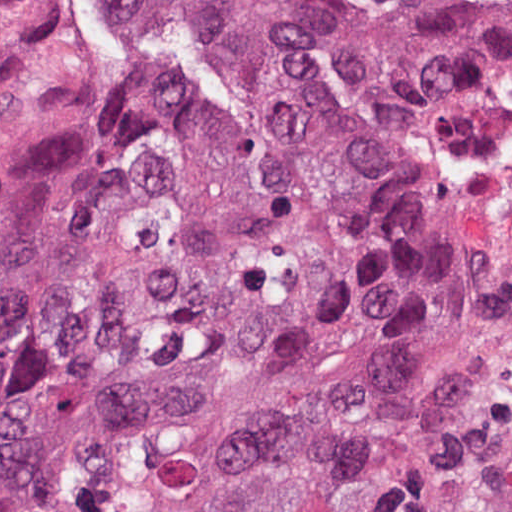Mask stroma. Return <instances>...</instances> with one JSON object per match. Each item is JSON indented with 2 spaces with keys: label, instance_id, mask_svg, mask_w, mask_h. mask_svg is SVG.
Segmentation results:
<instances>
[{
  "label": "stroma",
  "instance_id": "stroma-1",
  "mask_svg": "<svg viewBox=\"0 0 512 512\" xmlns=\"http://www.w3.org/2000/svg\"><path fill=\"white\" fill-rule=\"evenodd\" d=\"M169 0H0V512L18 507V391L58 262L164 126ZM472 333L500 397L512 512V155L467 258Z\"/></svg>",
  "mask_w": 512,
  "mask_h": 512
}]
</instances>
